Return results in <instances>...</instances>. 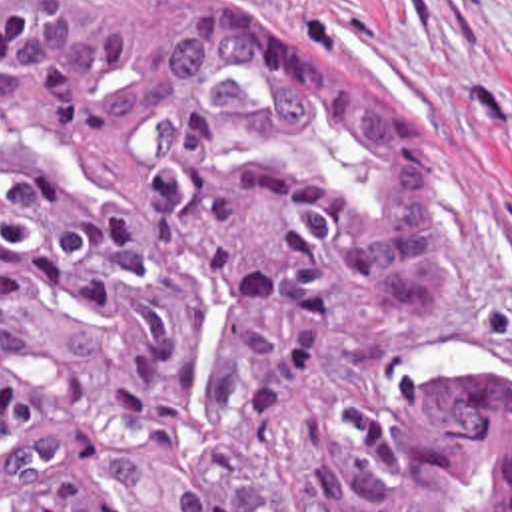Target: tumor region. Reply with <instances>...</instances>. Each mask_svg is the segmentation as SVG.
<instances>
[{
	"label": "tumor region",
	"instance_id": "obj_1",
	"mask_svg": "<svg viewBox=\"0 0 512 512\" xmlns=\"http://www.w3.org/2000/svg\"><path fill=\"white\" fill-rule=\"evenodd\" d=\"M442 203L246 0H0V512H512V403L394 391Z\"/></svg>",
	"mask_w": 512,
	"mask_h": 512
}]
</instances>
